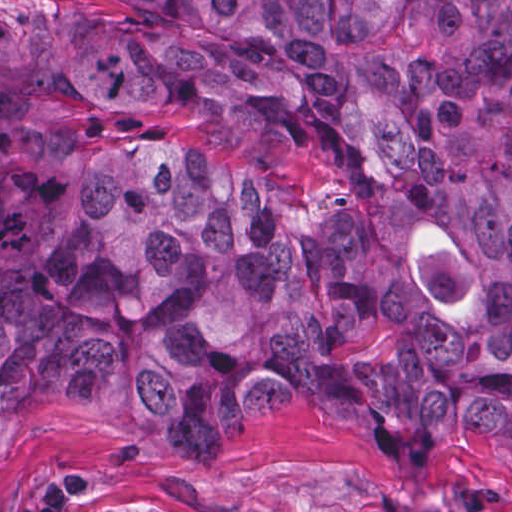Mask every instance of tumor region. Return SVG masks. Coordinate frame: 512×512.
I'll use <instances>...</instances> for the list:
<instances>
[{"label": "tumor region", "mask_w": 512, "mask_h": 512, "mask_svg": "<svg viewBox=\"0 0 512 512\" xmlns=\"http://www.w3.org/2000/svg\"><path fill=\"white\" fill-rule=\"evenodd\" d=\"M113 1L0 8V477L79 406L512 465V0Z\"/></svg>", "instance_id": "tumor-region-1"}]
</instances>
